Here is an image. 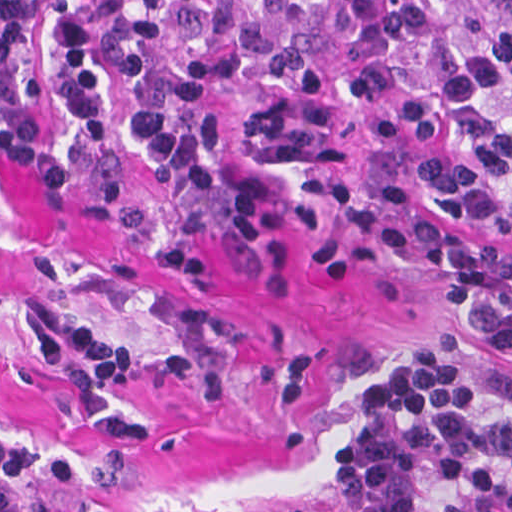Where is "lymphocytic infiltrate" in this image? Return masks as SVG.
I'll return each instance as SVG.
<instances>
[{
  "label": "lymphocytic infiltrate",
  "mask_w": 512,
  "mask_h": 512,
  "mask_svg": "<svg viewBox=\"0 0 512 512\" xmlns=\"http://www.w3.org/2000/svg\"><path fill=\"white\" fill-rule=\"evenodd\" d=\"M83 103L114 150L204 201L273 274L320 246L426 257L442 303L512 349V261L421 221L406 187L360 181L351 162L372 139L443 146L418 166L431 197L512 235V0H0V113ZM68 346L59 386L97 439L144 435L114 406L137 376L229 396L195 358L38 326L46 364ZM80 474L0 434V512H43L31 485L68 492ZM337 485L348 512H512V386L437 330L377 376Z\"/></svg>",
  "instance_id": "obj_1"
}]
</instances>
